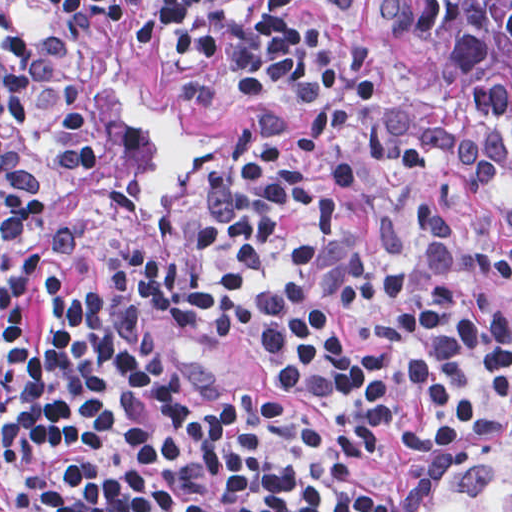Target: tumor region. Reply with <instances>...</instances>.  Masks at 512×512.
I'll return each instance as SVG.
<instances>
[{
  "label": "tumor region",
  "mask_w": 512,
  "mask_h": 512,
  "mask_svg": "<svg viewBox=\"0 0 512 512\" xmlns=\"http://www.w3.org/2000/svg\"><path fill=\"white\" fill-rule=\"evenodd\" d=\"M368 46L471 110L486 155L512 161V0H359ZM445 512H512V439L441 485Z\"/></svg>",
  "instance_id": "tumor-region-1"
}]
</instances>
